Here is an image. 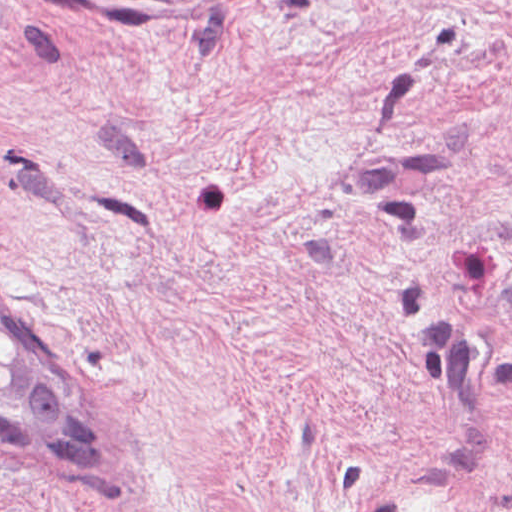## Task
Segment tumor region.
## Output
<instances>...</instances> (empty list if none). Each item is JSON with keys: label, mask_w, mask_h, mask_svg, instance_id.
Segmentation results:
<instances>
[{"label": "tumor region", "mask_w": 512, "mask_h": 512, "mask_svg": "<svg viewBox=\"0 0 512 512\" xmlns=\"http://www.w3.org/2000/svg\"><path fill=\"white\" fill-rule=\"evenodd\" d=\"M0 461L37 478L104 469L35 322L1 285Z\"/></svg>", "instance_id": "obj_1"}]
</instances>
